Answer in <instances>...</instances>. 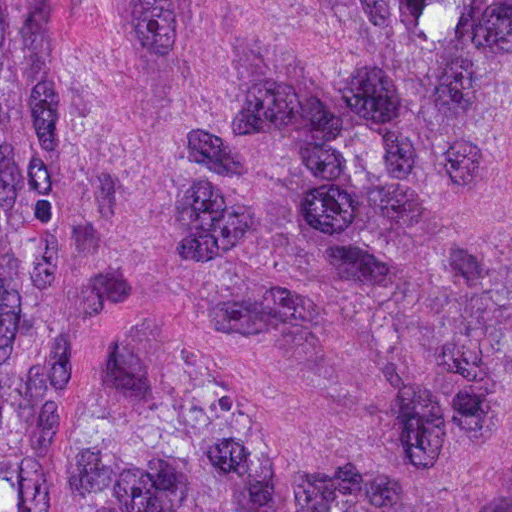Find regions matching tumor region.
Here are the masks:
<instances>
[{
	"label": "tumor region",
	"mask_w": 512,
	"mask_h": 512,
	"mask_svg": "<svg viewBox=\"0 0 512 512\" xmlns=\"http://www.w3.org/2000/svg\"><path fill=\"white\" fill-rule=\"evenodd\" d=\"M0 512H512V0H0Z\"/></svg>",
	"instance_id": "obj_1"
}]
</instances>
